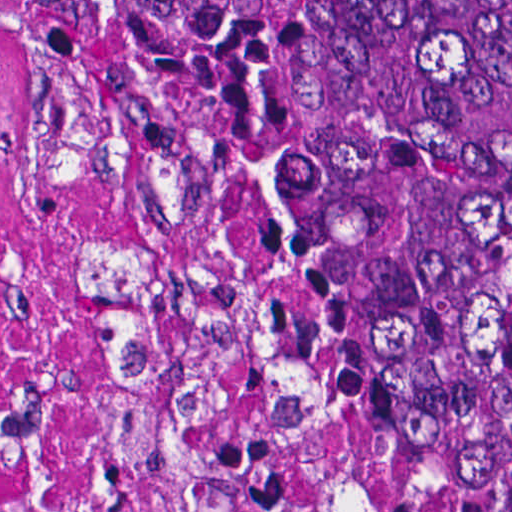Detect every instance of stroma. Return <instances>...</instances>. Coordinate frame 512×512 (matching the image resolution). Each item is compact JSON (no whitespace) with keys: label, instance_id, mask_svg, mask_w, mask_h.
<instances>
[{"label":"stroma","instance_id":"stroma-1","mask_svg":"<svg viewBox=\"0 0 512 512\" xmlns=\"http://www.w3.org/2000/svg\"><path fill=\"white\" fill-rule=\"evenodd\" d=\"M45 34V33H44ZM46 35V34H45ZM57 55L69 71L72 77L86 85L107 107H109L122 121L128 124L135 134L143 137L72 65V63L62 54L52 40L46 35ZM219 213V212H218ZM220 215V213H219ZM221 222L229 239L242 251L249 263L256 272L261 296L270 310L273 317L281 326L290 340L314 357L336 378L346 385L360 400H362L371 410L379 415L402 412L411 407L421 404L440 402L446 400H477L478 403L487 412L493 400L504 368L489 378L475 385L462 394H384L374 386L346 370L339 364L311 348L299 340L295 329L291 323L288 313L272 280L269 270L261 253L243 236H241L221 215ZM472 484L469 487L464 501L463 512L470 511Z\"/></svg>","mask_w":512,"mask_h":512}]
</instances>
